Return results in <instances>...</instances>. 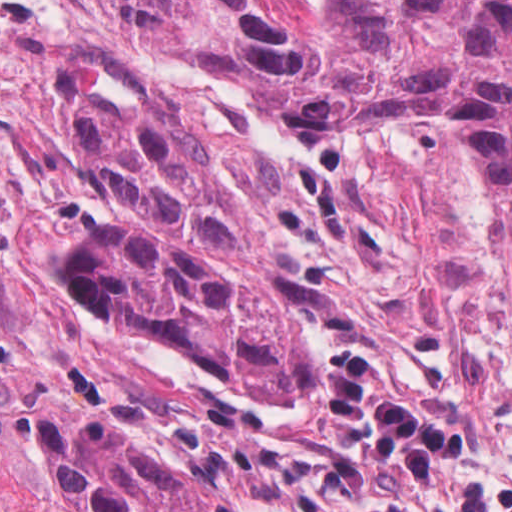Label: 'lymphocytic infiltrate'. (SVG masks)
<instances>
[{
  "label": "lymphocytic infiltrate",
  "instance_id": "1",
  "mask_svg": "<svg viewBox=\"0 0 512 512\" xmlns=\"http://www.w3.org/2000/svg\"><path fill=\"white\" fill-rule=\"evenodd\" d=\"M315 390L333 421L366 429L370 461L409 473L402 499L352 512H512V483L453 481L451 471L474 458V435L417 406L373 356L349 351L329 359Z\"/></svg>",
  "mask_w": 512,
  "mask_h": 512
}]
</instances>
